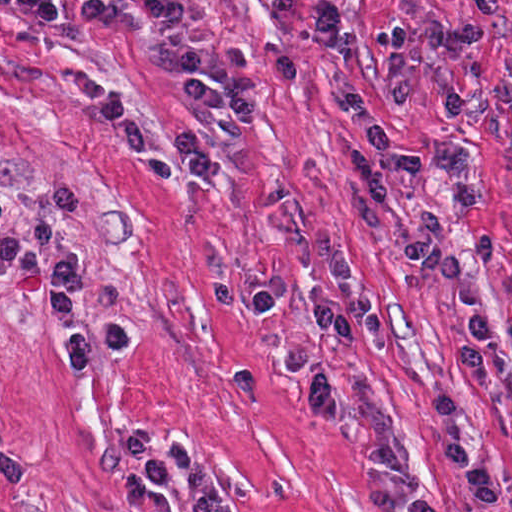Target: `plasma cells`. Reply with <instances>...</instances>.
<instances>
[{
  "instance_id": "plasma-cells-1",
  "label": "plasma cells",
  "mask_w": 512,
  "mask_h": 512,
  "mask_svg": "<svg viewBox=\"0 0 512 512\" xmlns=\"http://www.w3.org/2000/svg\"><path fill=\"white\" fill-rule=\"evenodd\" d=\"M38 30L42 43L81 97L92 105L114 134L125 155L161 178L176 176L172 161L156 152L138 121L100 82L71 56L59 32L63 20L56 0H17ZM468 11V26L456 28L439 17H427L414 26L380 33L376 48L388 58L393 80L384 90V100L375 105L353 80L345 62V15L340 0H317L314 8V54L330 83L332 96L367 148L356 149L349 158V175L366 203L380 207L390 195V180L412 176L421 168L418 147L396 137L385 110L414 102L415 67L423 47L450 54L458 63L457 80L442 97L447 124L464 128L492 112L504 129L512 152V83L483 77L480 51L505 25L499 0H461ZM225 99L241 124L255 123L260 96L270 87L293 86L300 73L289 54H278L266 76L253 73L239 47L226 46L223 55ZM435 169L448 183L454 213L465 215L493 201L484 188L477 157L468 143L443 147ZM329 265L342 298L341 323L352 331H364L384 353L392 352L388 325L370 294L363 288L350 257L330 256ZM284 278L273 277L257 288L247 289L222 281L213 286L217 303L224 309L240 308L254 315H271L282 305ZM188 491L174 507L143 482L136 472L124 470L117 487L125 504L135 512H230L216 488L210 467L193 462L183 469Z\"/></svg>"
}]
</instances>
